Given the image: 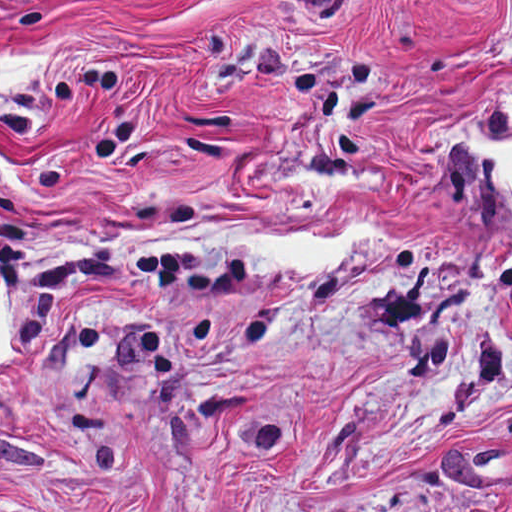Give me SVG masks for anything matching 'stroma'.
Wrapping results in <instances>:
<instances>
[{
    "instance_id": "stroma-1",
    "label": "stroma",
    "mask_w": 512,
    "mask_h": 512,
    "mask_svg": "<svg viewBox=\"0 0 512 512\" xmlns=\"http://www.w3.org/2000/svg\"><path fill=\"white\" fill-rule=\"evenodd\" d=\"M512 0H0V512H512ZM359 249L127 257L208 225Z\"/></svg>"
}]
</instances>
